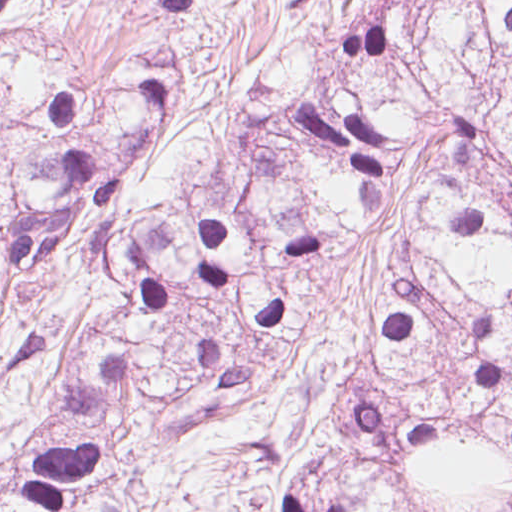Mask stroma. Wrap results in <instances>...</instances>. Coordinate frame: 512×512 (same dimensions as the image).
<instances>
[{"label": "stroma", "mask_w": 512, "mask_h": 512, "mask_svg": "<svg viewBox=\"0 0 512 512\" xmlns=\"http://www.w3.org/2000/svg\"><path fill=\"white\" fill-rule=\"evenodd\" d=\"M370 0H213L210 22L129 20L89 0H0V24L40 27L97 93L123 92L146 49L180 43L192 81L163 123L147 165L125 174L126 227L189 206L229 184L278 121L295 115L324 52ZM130 298L105 261L72 247L18 290L24 327L0 352V460H18L60 424L62 395L96 360V340Z\"/></svg>", "instance_id": "obj_1"}]
</instances>
